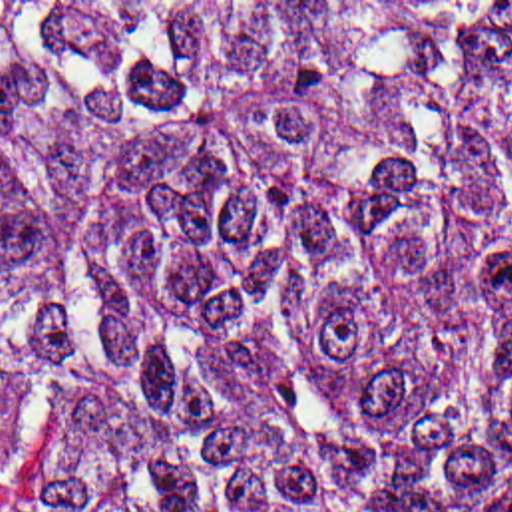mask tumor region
<instances>
[{
  "label": "tumor region",
  "instance_id": "tumor-region-1",
  "mask_svg": "<svg viewBox=\"0 0 512 512\" xmlns=\"http://www.w3.org/2000/svg\"><path fill=\"white\" fill-rule=\"evenodd\" d=\"M512 2H0V512H494Z\"/></svg>",
  "mask_w": 512,
  "mask_h": 512
}]
</instances>
